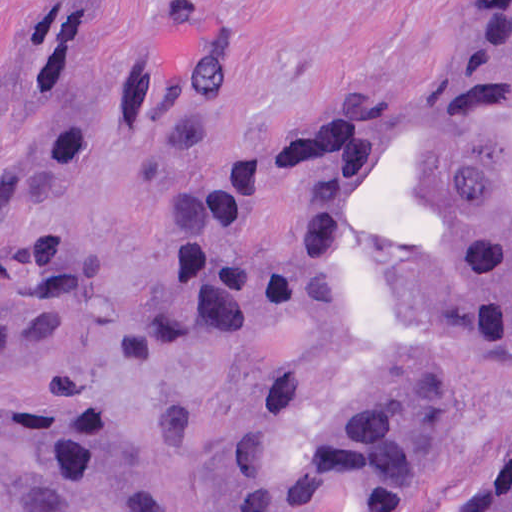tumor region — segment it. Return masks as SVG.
I'll use <instances>...</instances> for the list:
<instances>
[{"label":"tumor region","instance_id":"1","mask_svg":"<svg viewBox=\"0 0 512 512\" xmlns=\"http://www.w3.org/2000/svg\"><path fill=\"white\" fill-rule=\"evenodd\" d=\"M120 1L39 3L0 85V206L89 138L188 146L242 91L241 45L196 37L99 82ZM85 271L0 233V512H154L114 415L21 373L81 320ZM266 345L257 448L223 512H460L441 479L512 407V4L420 100L320 115L210 183L174 230L137 354ZM462 512H512V457Z\"/></svg>","mask_w":512,"mask_h":512}]
</instances>
